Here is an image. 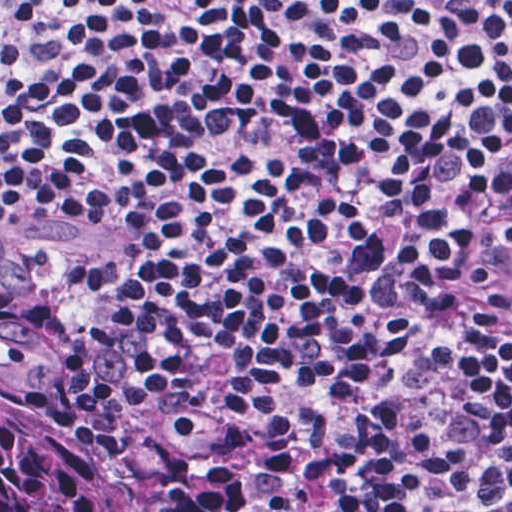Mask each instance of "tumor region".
<instances>
[{
	"label": "tumor region",
	"instance_id": "obj_1",
	"mask_svg": "<svg viewBox=\"0 0 512 512\" xmlns=\"http://www.w3.org/2000/svg\"><path fill=\"white\" fill-rule=\"evenodd\" d=\"M0 512H139L71 418V365L35 320L32 269L0 236Z\"/></svg>",
	"mask_w": 512,
	"mask_h": 512
}]
</instances>
